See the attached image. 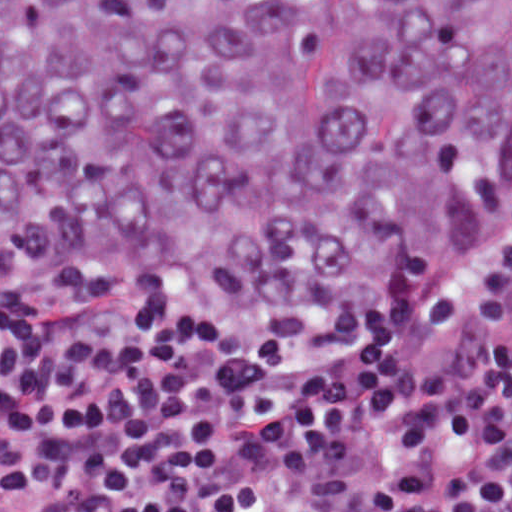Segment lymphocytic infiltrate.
<instances>
[{"label": "lymphocytic infiltrate", "instance_id": "f902f5d3", "mask_svg": "<svg viewBox=\"0 0 512 512\" xmlns=\"http://www.w3.org/2000/svg\"><path fill=\"white\" fill-rule=\"evenodd\" d=\"M0 512H512V248L398 357L0 302Z\"/></svg>", "mask_w": 512, "mask_h": 512}]
</instances>
